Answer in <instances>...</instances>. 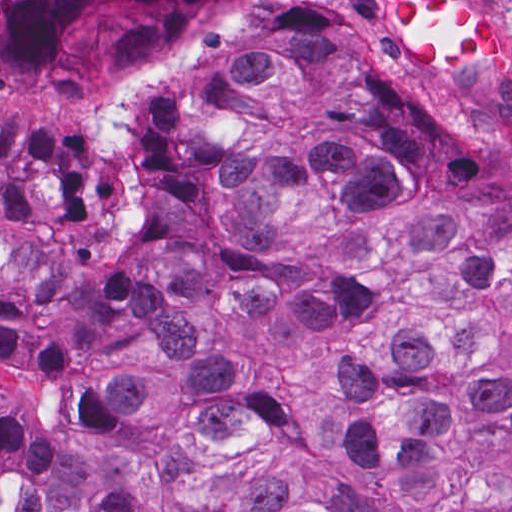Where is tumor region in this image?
<instances>
[{
    "instance_id": "tumor-region-1",
    "label": "tumor region",
    "mask_w": 512,
    "mask_h": 512,
    "mask_svg": "<svg viewBox=\"0 0 512 512\" xmlns=\"http://www.w3.org/2000/svg\"><path fill=\"white\" fill-rule=\"evenodd\" d=\"M221 0H0V83L166 63ZM273 6L157 79L127 181L0 130V512H512V126L405 80L508 54Z\"/></svg>"
}]
</instances>
